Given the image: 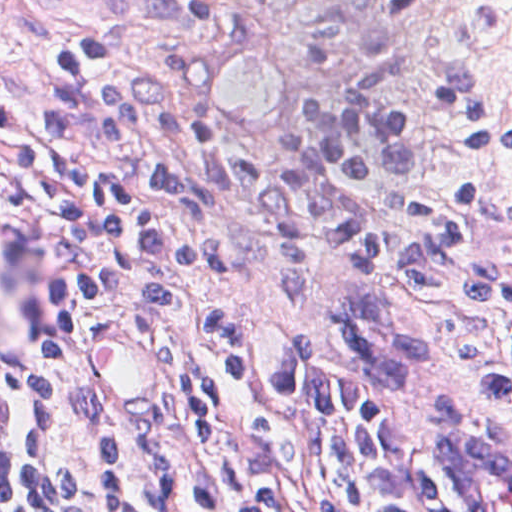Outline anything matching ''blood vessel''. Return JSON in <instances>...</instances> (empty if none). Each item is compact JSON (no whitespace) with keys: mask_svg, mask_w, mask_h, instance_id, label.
Returning <instances> with one entry per match:
<instances>
[{"mask_svg":"<svg viewBox=\"0 0 512 512\" xmlns=\"http://www.w3.org/2000/svg\"><path fill=\"white\" fill-rule=\"evenodd\" d=\"M264 44L229 42L210 62L216 108L225 124L246 140L277 135L291 106L282 62ZM88 366L107 408L130 423L147 422L170 389L172 353L155 331L126 318L98 320L88 345ZM435 459L457 512H512V447L472 430L440 425Z\"/></svg>","mask_w":512,"mask_h":512,"instance_id":"1","label":"blood vessel"}]
</instances>
